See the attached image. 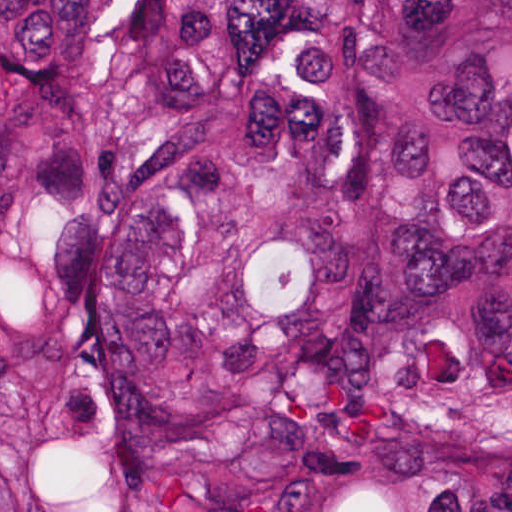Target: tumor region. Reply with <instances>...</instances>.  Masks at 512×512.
I'll return each instance as SVG.
<instances>
[{"label": "tumor region", "instance_id": "e687c5a6", "mask_svg": "<svg viewBox=\"0 0 512 512\" xmlns=\"http://www.w3.org/2000/svg\"><path fill=\"white\" fill-rule=\"evenodd\" d=\"M0 512H512V1H0Z\"/></svg>", "mask_w": 512, "mask_h": 512}]
</instances>
